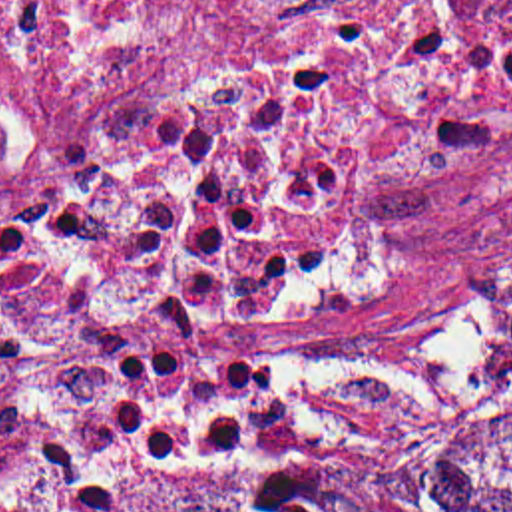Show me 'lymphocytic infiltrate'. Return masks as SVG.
<instances>
[{
    "mask_svg": "<svg viewBox=\"0 0 512 512\" xmlns=\"http://www.w3.org/2000/svg\"><path fill=\"white\" fill-rule=\"evenodd\" d=\"M41 197L0 213V512H111L180 452L270 434L278 338L216 221Z\"/></svg>",
    "mask_w": 512,
    "mask_h": 512,
    "instance_id": "obj_1",
    "label": "lymphocytic infiltrate"
}]
</instances>
